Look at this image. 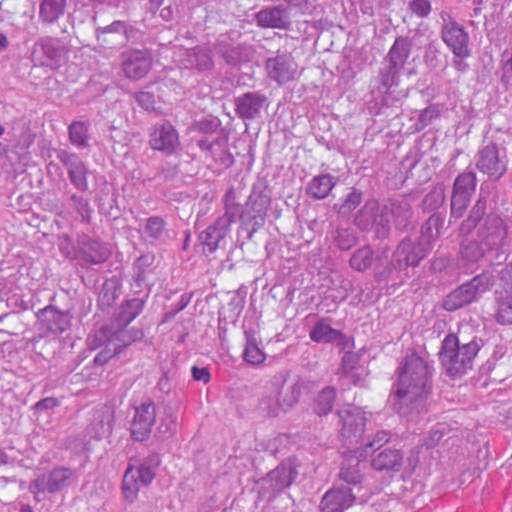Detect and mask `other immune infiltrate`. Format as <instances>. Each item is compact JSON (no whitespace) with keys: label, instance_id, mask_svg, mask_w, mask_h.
<instances>
[{"label":"other immune infiltrate","instance_id":"obj_1","mask_svg":"<svg viewBox=\"0 0 512 512\" xmlns=\"http://www.w3.org/2000/svg\"><path fill=\"white\" fill-rule=\"evenodd\" d=\"M325 239L339 262L418 271L447 298L512 326V151L471 141L468 152L406 185L329 188Z\"/></svg>","mask_w":512,"mask_h":512}]
</instances>
